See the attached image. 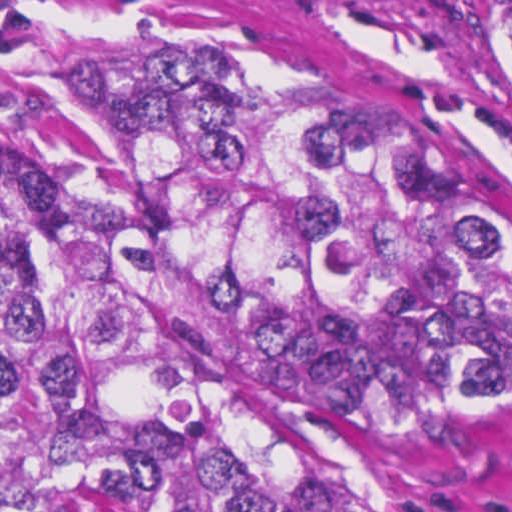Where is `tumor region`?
<instances>
[{"label": "tumor region", "instance_id": "e687c5a6", "mask_svg": "<svg viewBox=\"0 0 512 512\" xmlns=\"http://www.w3.org/2000/svg\"><path fill=\"white\" fill-rule=\"evenodd\" d=\"M512 73L463 0H354ZM43 101L102 189L0 192V512H350L270 371L398 424L512 395V249L375 90L292 46H168Z\"/></svg>", "mask_w": 512, "mask_h": 512}]
</instances>
